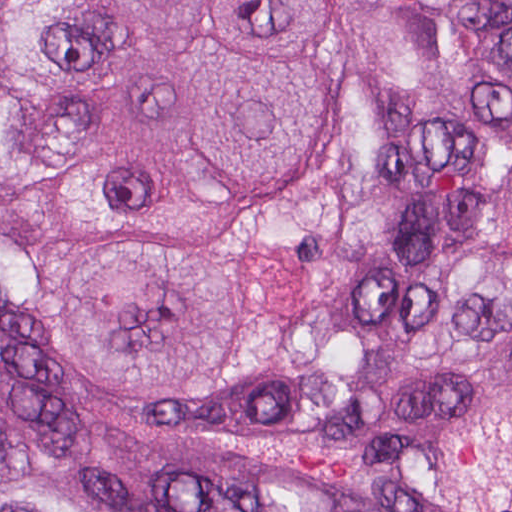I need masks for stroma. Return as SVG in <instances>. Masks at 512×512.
<instances>
[{
	"instance_id": "35a3bbf8",
	"label": "stroma",
	"mask_w": 512,
	"mask_h": 512,
	"mask_svg": "<svg viewBox=\"0 0 512 512\" xmlns=\"http://www.w3.org/2000/svg\"><path fill=\"white\" fill-rule=\"evenodd\" d=\"M326 49L329 79L348 106V126L314 184L238 244L240 268L257 304L260 357L245 384L217 401H120L94 390L65 367L46 316L53 290L94 257L86 239L49 213L56 186L0 195V214H18L54 244L60 264L18 324L21 351L40 388L80 434L89 455L92 512H106L112 484L205 476L243 484H277L330 497L358 512H445L348 460L263 445L179 437L199 424H224L259 402L290 295L296 243L349 181L362 152V101L346 45L343 0H334Z\"/></svg>"
}]
</instances>
